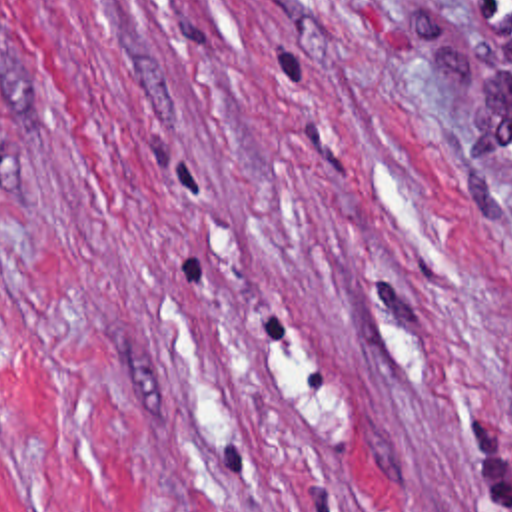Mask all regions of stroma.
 <instances>
[{"label":"stroma","mask_w":512,"mask_h":512,"mask_svg":"<svg viewBox=\"0 0 512 512\" xmlns=\"http://www.w3.org/2000/svg\"><path fill=\"white\" fill-rule=\"evenodd\" d=\"M0 512H512V0H0Z\"/></svg>","instance_id":"stroma-1"}]
</instances>
